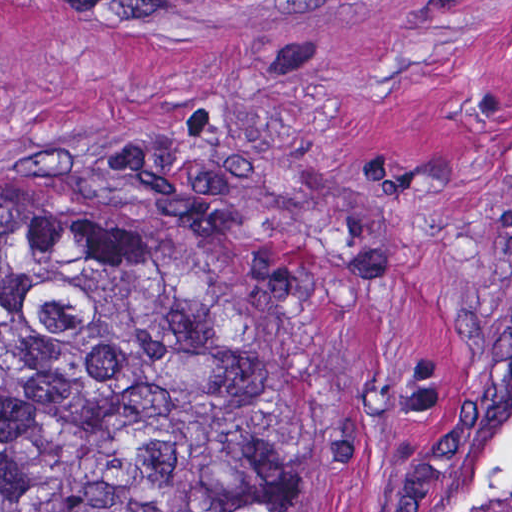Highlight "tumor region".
Masks as SVG:
<instances>
[{"instance_id":"obj_1","label":"tumor region","mask_w":512,"mask_h":512,"mask_svg":"<svg viewBox=\"0 0 512 512\" xmlns=\"http://www.w3.org/2000/svg\"><path fill=\"white\" fill-rule=\"evenodd\" d=\"M311 309L297 196L159 131L0 190V512H289Z\"/></svg>"}]
</instances>
